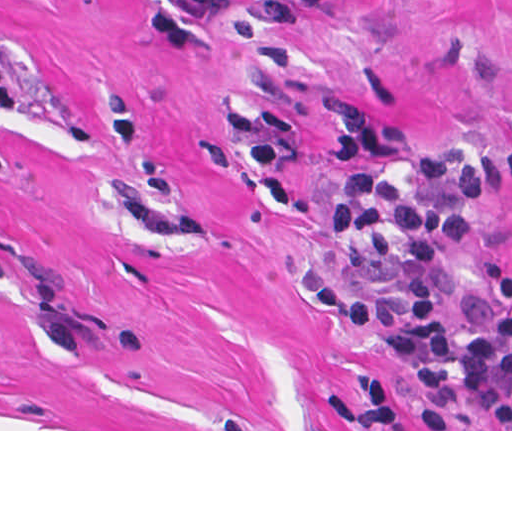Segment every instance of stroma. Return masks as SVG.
I'll return each mask as SVG.
<instances>
[{"label": "stroma", "instance_id": "obj_1", "mask_svg": "<svg viewBox=\"0 0 512 512\" xmlns=\"http://www.w3.org/2000/svg\"><path fill=\"white\" fill-rule=\"evenodd\" d=\"M148 0H0V431L459 429L393 333L512 273V186L444 242L434 316L352 328L306 295L315 271L386 294L381 256L330 235L335 111L421 151L512 150V0H328L284 35L232 0L188 46L146 37Z\"/></svg>", "mask_w": 512, "mask_h": 512}]
</instances>
